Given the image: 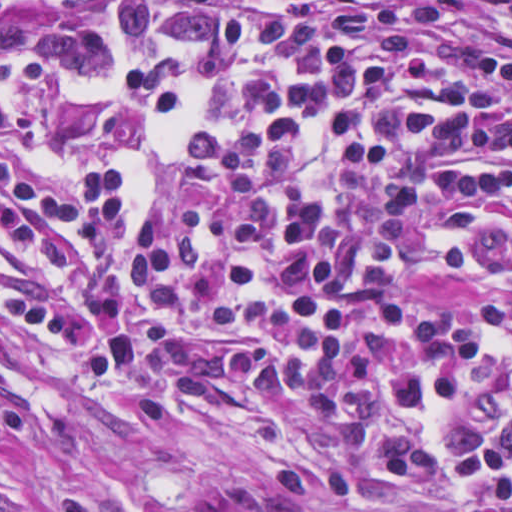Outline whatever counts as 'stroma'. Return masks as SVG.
Returning <instances> with one entry per match:
<instances>
[{
	"label": "stroma",
	"instance_id": "35a3bbf8",
	"mask_svg": "<svg viewBox=\"0 0 512 512\" xmlns=\"http://www.w3.org/2000/svg\"><path fill=\"white\" fill-rule=\"evenodd\" d=\"M504 30L506 0H446ZM137 0H103L43 18H1L0 0V512H58L64 491L91 512H213L217 470L308 441L332 424L328 406L441 404L458 377L512 335V318L464 357L341 378L288 394H232L147 385L87 392L10 361L1 345V165L107 168L121 208L148 216L179 190L174 139L189 125L143 115L121 92L28 72L56 57L114 50ZM383 512H431L400 497Z\"/></svg>",
	"mask_w": 512,
	"mask_h": 512
}]
</instances>
